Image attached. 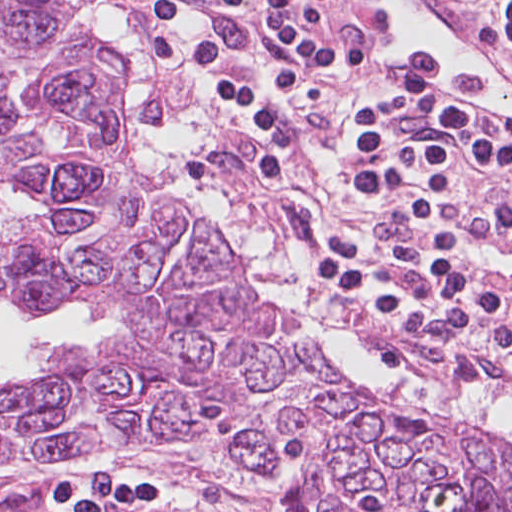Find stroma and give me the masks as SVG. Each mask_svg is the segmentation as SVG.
<instances>
[{
	"label": "stroma",
	"instance_id": "obj_1",
	"mask_svg": "<svg viewBox=\"0 0 512 512\" xmlns=\"http://www.w3.org/2000/svg\"><path fill=\"white\" fill-rule=\"evenodd\" d=\"M114 2L140 29L151 72L145 89L151 119L176 121L194 108L203 113L210 132L185 156L189 172L217 191L243 226L262 238L283 241L313 283L311 267L334 235L352 232L374 244L381 238V227L369 215L353 177L354 127H386L412 148L418 177L453 226L422 168L420 148L409 129L473 128L458 114H407L394 121H354L343 102L319 94L311 101L306 121H224V108L213 95L155 59L147 31L155 0ZM304 127L306 133L294 149L292 175L282 184L266 183L237 140ZM126 143L141 171L127 136ZM161 188L167 190L164 185ZM472 250L512 288L509 274ZM244 259V278L253 293L249 255ZM317 290L345 329L381 344L398 360L476 394L492 388L512 392V383L477 350L452 341L436 311L416 334L399 337L383 329L381 320L364 301L334 298ZM509 303L505 324L512 336V293ZM7 306L16 309L14 303L0 300V308ZM105 346L83 348L97 352ZM331 360L347 384L365 396H400L372 392L355 374ZM284 480L225 453L194 448L19 454L0 461V512H280L271 494Z\"/></svg>",
	"mask_w": 512,
	"mask_h": 512
}]
</instances>
